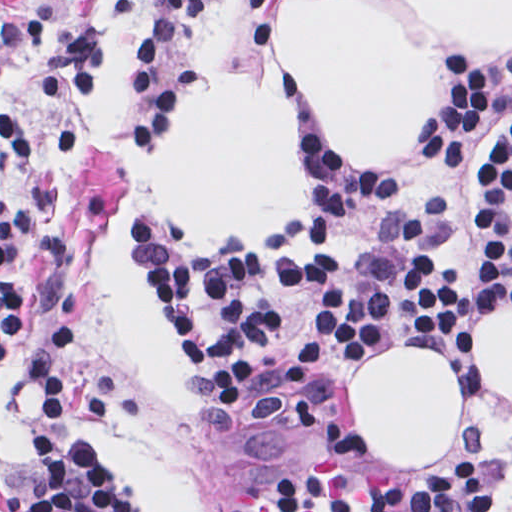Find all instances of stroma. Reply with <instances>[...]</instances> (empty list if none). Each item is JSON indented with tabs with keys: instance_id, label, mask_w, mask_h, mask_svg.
<instances>
[{
	"instance_id": "stroma-1",
	"label": "stroma",
	"mask_w": 512,
	"mask_h": 512,
	"mask_svg": "<svg viewBox=\"0 0 512 512\" xmlns=\"http://www.w3.org/2000/svg\"><path fill=\"white\" fill-rule=\"evenodd\" d=\"M277 1H391L435 61L437 103L450 61L489 76H512V46H483L426 29L410 5L512 0H0V24H22L40 15L64 31L96 27L104 38L99 83L76 100L45 94L38 39L24 40L0 57V113L17 124L27 149L25 160L0 169V211L9 197L36 188L53 220V231L22 249L20 303L0 353V512H29L27 497L36 484L29 365L63 317L81 321L74 365L76 423L136 512H249L276 462L310 430L330 475L349 483H415L429 468L383 464L349 398L351 372L398 345L393 343L424 345L450 363L465 386V425L455 448L483 455L484 512H512V476L506 467L512 401L470 360L474 325L511 304L478 316L463 332L401 324L376 333L341 357L304 419L284 434H262L234 407L210 365L162 311L186 356V380L206 409L174 408L137 368L108 297L100 250L123 201L138 232L136 245L128 242L126 251L139 271L148 251L272 243L291 236L307 212L272 235H209L161 208L152 178L194 91L226 77L265 87L289 105L294 101L297 149L314 198L322 152L337 174L403 177L418 162L434 122L437 103L412 153L377 169L351 165L323 117L279 67ZM511 123L512 109L495 106L455 171H420L404 190L349 216L334 238H291L283 241V253L299 260L348 255L376 221L399 212L427 228L444 262L480 277L484 256L473 227L471 191Z\"/></svg>"
}]
</instances>
